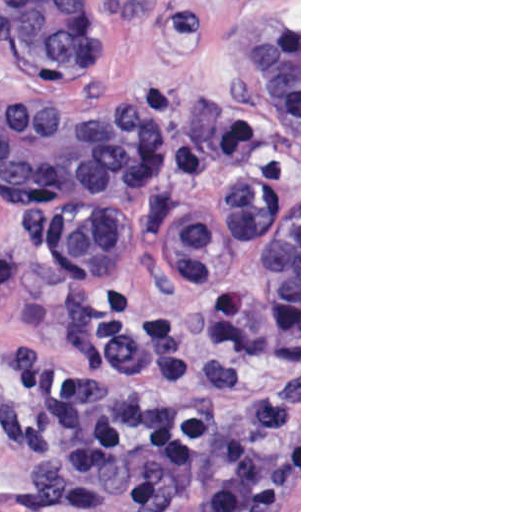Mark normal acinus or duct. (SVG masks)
Listing matches in <instances>:
<instances>
[{
    "mask_svg": "<svg viewBox=\"0 0 512 512\" xmlns=\"http://www.w3.org/2000/svg\"><path fill=\"white\" fill-rule=\"evenodd\" d=\"M6 45L44 89L0 109V191L36 205L49 245L85 276L120 268L124 198L139 133L82 88L97 60V0H10ZM225 71L252 111L299 141V33L222 34ZM263 309L299 329V199L266 227Z\"/></svg>",
    "mask_w": 512,
    "mask_h": 512,
    "instance_id": "30e58d81",
    "label": "normal acinus or duct"
}]
</instances>
